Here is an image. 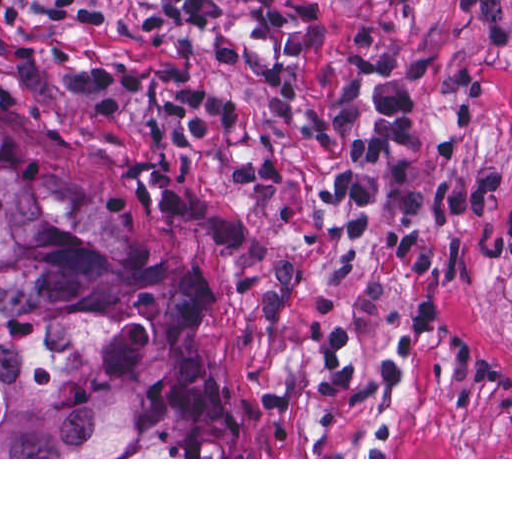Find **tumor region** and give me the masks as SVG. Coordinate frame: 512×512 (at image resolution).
Here are the masks:
<instances>
[{
	"instance_id": "e687c5a6",
	"label": "tumor region",
	"mask_w": 512,
	"mask_h": 512,
	"mask_svg": "<svg viewBox=\"0 0 512 512\" xmlns=\"http://www.w3.org/2000/svg\"><path fill=\"white\" fill-rule=\"evenodd\" d=\"M0 457H243L197 270L1 116Z\"/></svg>"
}]
</instances>
